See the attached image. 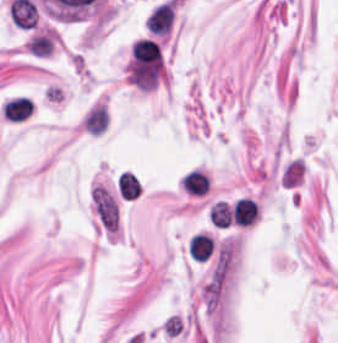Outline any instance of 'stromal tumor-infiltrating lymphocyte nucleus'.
I'll use <instances>...</instances> for the list:
<instances>
[{
	"instance_id": "obj_1",
	"label": "stromal tumor-infiltrating lymphocyte nucleus",
	"mask_w": 338,
	"mask_h": 343,
	"mask_svg": "<svg viewBox=\"0 0 338 343\" xmlns=\"http://www.w3.org/2000/svg\"><path fill=\"white\" fill-rule=\"evenodd\" d=\"M182 191L194 198H205L213 183L210 171L194 166L183 172L178 180Z\"/></svg>"
},
{
	"instance_id": "obj_2",
	"label": "stromal tumor-infiltrating lymphocyte nucleus",
	"mask_w": 338,
	"mask_h": 343,
	"mask_svg": "<svg viewBox=\"0 0 338 343\" xmlns=\"http://www.w3.org/2000/svg\"><path fill=\"white\" fill-rule=\"evenodd\" d=\"M232 215L235 224L248 226L255 223L259 216V209L255 201L241 198L236 201Z\"/></svg>"
},
{
	"instance_id": "obj_3",
	"label": "stromal tumor-infiltrating lymphocyte nucleus",
	"mask_w": 338,
	"mask_h": 343,
	"mask_svg": "<svg viewBox=\"0 0 338 343\" xmlns=\"http://www.w3.org/2000/svg\"><path fill=\"white\" fill-rule=\"evenodd\" d=\"M213 247L208 235L196 234L188 245V256L197 262H205L209 259Z\"/></svg>"
},
{
	"instance_id": "obj_4",
	"label": "stromal tumor-infiltrating lymphocyte nucleus",
	"mask_w": 338,
	"mask_h": 343,
	"mask_svg": "<svg viewBox=\"0 0 338 343\" xmlns=\"http://www.w3.org/2000/svg\"><path fill=\"white\" fill-rule=\"evenodd\" d=\"M108 114L106 107H92L85 117L84 128L91 134H100L107 127Z\"/></svg>"
},
{
	"instance_id": "obj_5",
	"label": "stromal tumor-infiltrating lymphocyte nucleus",
	"mask_w": 338,
	"mask_h": 343,
	"mask_svg": "<svg viewBox=\"0 0 338 343\" xmlns=\"http://www.w3.org/2000/svg\"><path fill=\"white\" fill-rule=\"evenodd\" d=\"M29 52L36 57H49L53 48V39L45 32L37 34L27 42Z\"/></svg>"
},
{
	"instance_id": "obj_6",
	"label": "stromal tumor-infiltrating lymphocyte nucleus",
	"mask_w": 338,
	"mask_h": 343,
	"mask_svg": "<svg viewBox=\"0 0 338 343\" xmlns=\"http://www.w3.org/2000/svg\"><path fill=\"white\" fill-rule=\"evenodd\" d=\"M117 186L122 198L134 200L141 193L139 181L129 172L121 173Z\"/></svg>"
},
{
	"instance_id": "obj_7",
	"label": "stromal tumor-infiltrating lymphocyte nucleus",
	"mask_w": 338,
	"mask_h": 343,
	"mask_svg": "<svg viewBox=\"0 0 338 343\" xmlns=\"http://www.w3.org/2000/svg\"><path fill=\"white\" fill-rule=\"evenodd\" d=\"M209 215L215 226L226 229L232 220V208L219 201L213 205Z\"/></svg>"
}]
</instances>
